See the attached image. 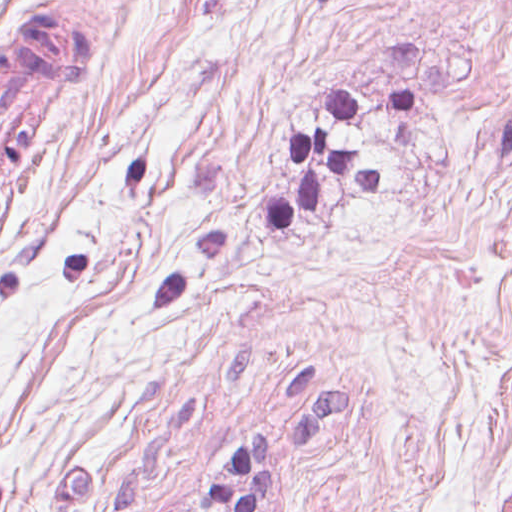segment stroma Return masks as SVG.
Returning a JSON list of instances; mask_svg holds the SVG:
<instances>
[{"label": "stroma", "instance_id": "35a3bbf8", "mask_svg": "<svg viewBox=\"0 0 512 512\" xmlns=\"http://www.w3.org/2000/svg\"><path fill=\"white\" fill-rule=\"evenodd\" d=\"M90 63L1 215L0 512H512V0H0ZM327 131L381 192L324 169ZM4 114L0 109V154Z\"/></svg>", "mask_w": 512, "mask_h": 512}]
</instances>
